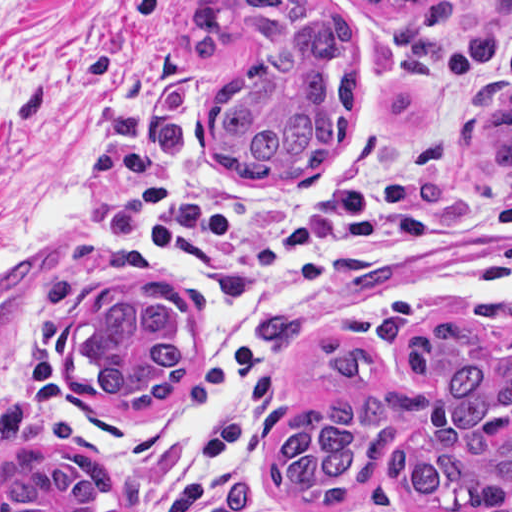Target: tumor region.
Listing matches in <instances>:
<instances>
[{
  "mask_svg": "<svg viewBox=\"0 0 512 512\" xmlns=\"http://www.w3.org/2000/svg\"><path fill=\"white\" fill-rule=\"evenodd\" d=\"M396 34L410 73L438 75L449 61L454 0H361ZM193 49L220 60L254 32L256 55L220 82L208 134L217 169L245 181H303L344 146L360 108V45L313 0H198L188 10ZM447 133L458 151L512 177V83L491 81L466 99ZM507 340L486 355L471 323L430 319L401 351L411 370L441 385L422 391L390 376L364 341L326 333L322 351L346 393L301 413L276 448L272 482L283 498L345 501L396 459L401 512H512V302L482 313ZM187 305L154 286H126L89 304L78 360L110 401L158 409L190 365ZM109 475L75 449L68 458L39 441L33 415L0 405V512H106Z\"/></svg>",
  "mask_w": 512,
  "mask_h": 512,
  "instance_id": "obj_1",
  "label": "tumor region"
}]
</instances>
